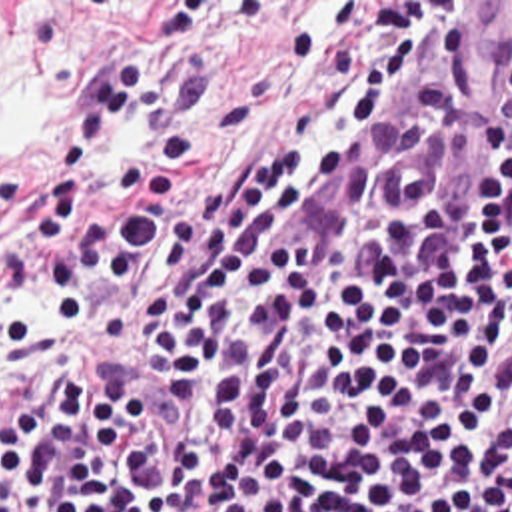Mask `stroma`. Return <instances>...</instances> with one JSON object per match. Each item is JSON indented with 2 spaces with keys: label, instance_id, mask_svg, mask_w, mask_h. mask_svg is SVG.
<instances>
[{
  "label": "stroma",
  "instance_id": "stroma-1",
  "mask_svg": "<svg viewBox=\"0 0 512 512\" xmlns=\"http://www.w3.org/2000/svg\"><path fill=\"white\" fill-rule=\"evenodd\" d=\"M169 2H211V14L179 46L171 68L173 78L193 56L211 60V90L195 112L199 150L181 166L163 136L147 128L119 130L75 192L77 242L137 200L113 186L117 158L167 162L177 176L173 202L183 200L234 166L268 158L294 134L304 108L340 98L372 62L390 58L398 42L448 34L460 2L512 0H0L3 387L25 391L63 353L93 349L101 361L119 365L155 421L181 445L185 419L155 389L153 361L133 337V299L163 274L169 254L155 252L131 280L101 282L77 327L37 294L27 236L77 98L111 62L157 44Z\"/></svg>",
  "mask_w": 512,
  "mask_h": 512
}]
</instances>
